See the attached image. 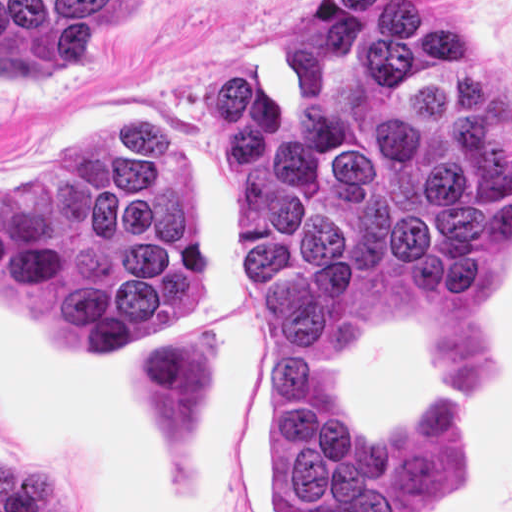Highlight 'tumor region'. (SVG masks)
<instances>
[{
  "mask_svg": "<svg viewBox=\"0 0 512 512\" xmlns=\"http://www.w3.org/2000/svg\"><path fill=\"white\" fill-rule=\"evenodd\" d=\"M146 0H0V76L96 63ZM282 66L213 68L215 139L237 183L245 316L271 401V512H418L457 476L451 396L414 432L364 427L340 392L361 292L473 297L512 244V93L431 0H310ZM0 292L90 354L130 351L145 448L224 455V335L174 325L208 304V260L151 128L90 132L0 187Z\"/></svg>",
  "mask_w": 512,
  "mask_h": 512,
  "instance_id": "e687c5a6",
  "label": "tumor region"
}]
</instances>
